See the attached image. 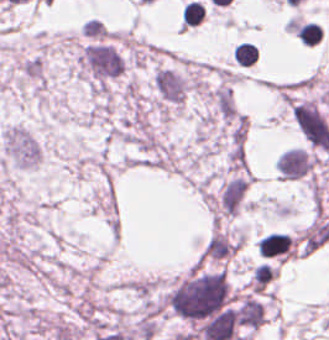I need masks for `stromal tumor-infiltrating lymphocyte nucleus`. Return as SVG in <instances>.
<instances>
[{
    "label": "stromal tumor-infiltrating lymphocyte nucleus",
    "instance_id": "2",
    "mask_svg": "<svg viewBox=\"0 0 329 340\" xmlns=\"http://www.w3.org/2000/svg\"><path fill=\"white\" fill-rule=\"evenodd\" d=\"M204 17V5L197 0H190L183 7L180 23L185 27L197 25Z\"/></svg>",
    "mask_w": 329,
    "mask_h": 340
},
{
    "label": "stromal tumor-infiltrating lymphocyte nucleus",
    "instance_id": "1",
    "mask_svg": "<svg viewBox=\"0 0 329 340\" xmlns=\"http://www.w3.org/2000/svg\"><path fill=\"white\" fill-rule=\"evenodd\" d=\"M232 56L242 66H249L257 61L258 49L248 41H241L232 49Z\"/></svg>",
    "mask_w": 329,
    "mask_h": 340
}]
</instances>
